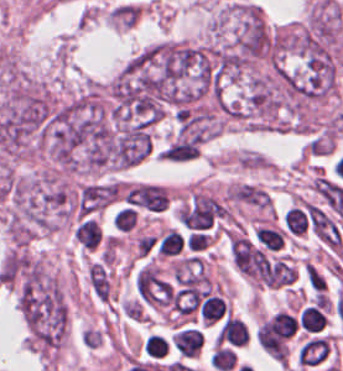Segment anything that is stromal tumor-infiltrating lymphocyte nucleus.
<instances>
[{"label": "stromal tumor-infiltrating lymphocyte nucleus", "mask_w": 343, "mask_h": 371, "mask_svg": "<svg viewBox=\"0 0 343 371\" xmlns=\"http://www.w3.org/2000/svg\"><path fill=\"white\" fill-rule=\"evenodd\" d=\"M333 351L332 340L327 334L307 337L298 349L300 366L311 368L325 364Z\"/></svg>", "instance_id": "obj_1"}, {"label": "stromal tumor-infiltrating lymphocyte nucleus", "mask_w": 343, "mask_h": 371, "mask_svg": "<svg viewBox=\"0 0 343 371\" xmlns=\"http://www.w3.org/2000/svg\"><path fill=\"white\" fill-rule=\"evenodd\" d=\"M75 241L90 250L97 249L103 243L100 222L92 216L79 220L75 225Z\"/></svg>", "instance_id": "obj_2"}, {"label": "stromal tumor-infiltrating lymphocyte nucleus", "mask_w": 343, "mask_h": 371, "mask_svg": "<svg viewBox=\"0 0 343 371\" xmlns=\"http://www.w3.org/2000/svg\"><path fill=\"white\" fill-rule=\"evenodd\" d=\"M286 239V230L280 226L257 225L252 241L267 252H275L283 248Z\"/></svg>", "instance_id": "obj_3"}, {"label": "stromal tumor-infiltrating lymphocyte nucleus", "mask_w": 343, "mask_h": 371, "mask_svg": "<svg viewBox=\"0 0 343 371\" xmlns=\"http://www.w3.org/2000/svg\"><path fill=\"white\" fill-rule=\"evenodd\" d=\"M283 223L293 236H302L307 228V219L304 213L293 206L285 211Z\"/></svg>", "instance_id": "obj_4"}, {"label": "stromal tumor-infiltrating lymphocyte nucleus", "mask_w": 343, "mask_h": 371, "mask_svg": "<svg viewBox=\"0 0 343 371\" xmlns=\"http://www.w3.org/2000/svg\"><path fill=\"white\" fill-rule=\"evenodd\" d=\"M112 222L114 227H116L120 231L131 232L137 226L138 222L137 210H134L124 205L118 209Z\"/></svg>", "instance_id": "obj_5"}, {"label": "stromal tumor-infiltrating lymphocyte nucleus", "mask_w": 343, "mask_h": 371, "mask_svg": "<svg viewBox=\"0 0 343 371\" xmlns=\"http://www.w3.org/2000/svg\"><path fill=\"white\" fill-rule=\"evenodd\" d=\"M143 348L146 355L155 359H162L168 352L169 346L158 334H151L144 342Z\"/></svg>", "instance_id": "obj_6"}]
</instances>
